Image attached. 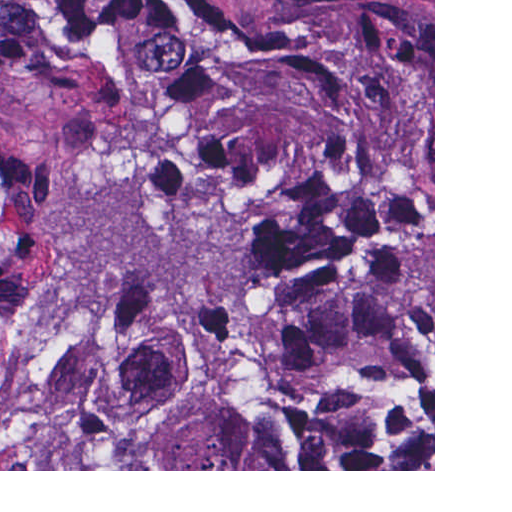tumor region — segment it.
Wrapping results in <instances>:
<instances>
[{
	"mask_svg": "<svg viewBox=\"0 0 512 512\" xmlns=\"http://www.w3.org/2000/svg\"><path fill=\"white\" fill-rule=\"evenodd\" d=\"M32 469H433V0H0Z\"/></svg>",
	"mask_w": 512,
	"mask_h": 512,
	"instance_id": "1",
	"label": "tumor region"
}]
</instances>
